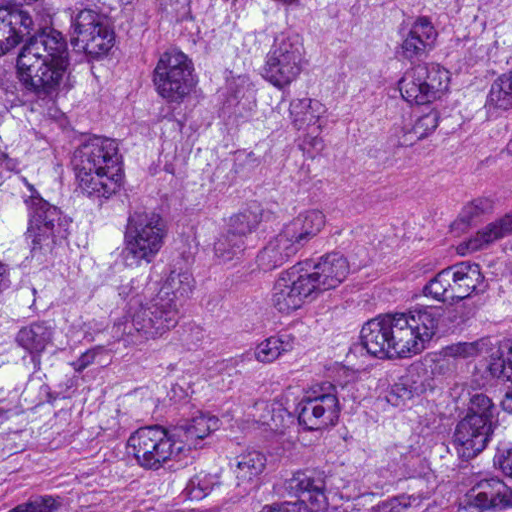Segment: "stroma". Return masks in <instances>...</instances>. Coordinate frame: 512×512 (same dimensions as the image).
I'll return each instance as SVG.
<instances>
[{"label":"stroma","mask_w":512,"mask_h":512,"mask_svg":"<svg viewBox=\"0 0 512 512\" xmlns=\"http://www.w3.org/2000/svg\"><path fill=\"white\" fill-rule=\"evenodd\" d=\"M343 240L512 247V154L423 156L379 167L339 218Z\"/></svg>","instance_id":"1"}]
</instances>
